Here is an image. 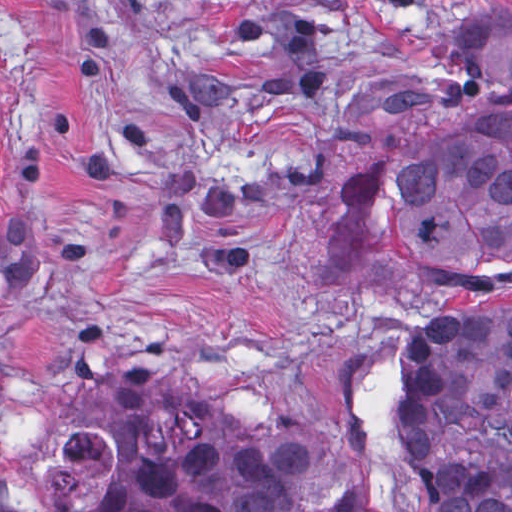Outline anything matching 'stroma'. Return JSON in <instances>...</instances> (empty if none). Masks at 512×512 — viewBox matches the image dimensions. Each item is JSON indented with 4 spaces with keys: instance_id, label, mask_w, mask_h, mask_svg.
<instances>
[{
    "instance_id": "obj_1",
    "label": "stroma",
    "mask_w": 512,
    "mask_h": 512,
    "mask_svg": "<svg viewBox=\"0 0 512 512\" xmlns=\"http://www.w3.org/2000/svg\"><path fill=\"white\" fill-rule=\"evenodd\" d=\"M0 0V512H95L178 450L181 385L298 415L373 357L396 512L399 353L512 289V246L397 264L337 189L398 133L497 98L443 53L512 0Z\"/></svg>"
}]
</instances>
